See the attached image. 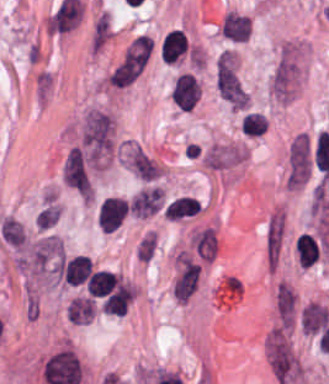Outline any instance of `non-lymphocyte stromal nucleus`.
<instances>
[{"label":"non-lymphocyte stromal nucleus","instance_id":"obj_1","mask_svg":"<svg viewBox=\"0 0 329 384\" xmlns=\"http://www.w3.org/2000/svg\"><path fill=\"white\" fill-rule=\"evenodd\" d=\"M78 146L91 169L108 159L112 147L108 113L89 108L81 119Z\"/></svg>","mask_w":329,"mask_h":384},{"label":"non-lymphocyte stromal nucleus","instance_id":"obj_2","mask_svg":"<svg viewBox=\"0 0 329 384\" xmlns=\"http://www.w3.org/2000/svg\"><path fill=\"white\" fill-rule=\"evenodd\" d=\"M64 249L57 235H43L28 243L20 265L35 274L52 273L61 264Z\"/></svg>","mask_w":329,"mask_h":384},{"label":"non-lymphocyte stromal nucleus","instance_id":"obj_3","mask_svg":"<svg viewBox=\"0 0 329 384\" xmlns=\"http://www.w3.org/2000/svg\"><path fill=\"white\" fill-rule=\"evenodd\" d=\"M150 39L132 38L109 73L110 85L129 86L149 61Z\"/></svg>","mask_w":329,"mask_h":384},{"label":"non-lymphocyte stromal nucleus","instance_id":"obj_4","mask_svg":"<svg viewBox=\"0 0 329 384\" xmlns=\"http://www.w3.org/2000/svg\"><path fill=\"white\" fill-rule=\"evenodd\" d=\"M268 363L281 384L293 382L301 373L299 360L282 335H269Z\"/></svg>","mask_w":329,"mask_h":384},{"label":"non-lymphocyte stromal nucleus","instance_id":"obj_5","mask_svg":"<svg viewBox=\"0 0 329 384\" xmlns=\"http://www.w3.org/2000/svg\"><path fill=\"white\" fill-rule=\"evenodd\" d=\"M286 236V217L278 204L268 214L263 227V260L266 271H274Z\"/></svg>","mask_w":329,"mask_h":384},{"label":"non-lymphocyte stromal nucleus","instance_id":"obj_6","mask_svg":"<svg viewBox=\"0 0 329 384\" xmlns=\"http://www.w3.org/2000/svg\"><path fill=\"white\" fill-rule=\"evenodd\" d=\"M63 181L84 197H92L90 162L84 149L73 147L64 158Z\"/></svg>","mask_w":329,"mask_h":384},{"label":"non-lymphocyte stromal nucleus","instance_id":"obj_7","mask_svg":"<svg viewBox=\"0 0 329 384\" xmlns=\"http://www.w3.org/2000/svg\"><path fill=\"white\" fill-rule=\"evenodd\" d=\"M215 83L219 97H240V79L229 50H222L216 59Z\"/></svg>","mask_w":329,"mask_h":384},{"label":"non-lymphocyte stromal nucleus","instance_id":"obj_8","mask_svg":"<svg viewBox=\"0 0 329 384\" xmlns=\"http://www.w3.org/2000/svg\"><path fill=\"white\" fill-rule=\"evenodd\" d=\"M199 269L195 261L185 252L178 251L175 254L173 292L175 298L187 301L192 294Z\"/></svg>","mask_w":329,"mask_h":384},{"label":"non-lymphocyte stromal nucleus","instance_id":"obj_9","mask_svg":"<svg viewBox=\"0 0 329 384\" xmlns=\"http://www.w3.org/2000/svg\"><path fill=\"white\" fill-rule=\"evenodd\" d=\"M163 208V194L160 186L146 183L128 197V214L145 218Z\"/></svg>","mask_w":329,"mask_h":384},{"label":"non-lymphocyte stromal nucleus","instance_id":"obj_10","mask_svg":"<svg viewBox=\"0 0 329 384\" xmlns=\"http://www.w3.org/2000/svg\"><path fill=\"white\" fill-rule=\"evenodd\" d=\"M96 217L101 229L112 233L126 219V198L107 196L97 206Z\"/></svg>","mask_w":329,"mask_h":384},{"label":"non-lymphocyte stromal nucleus","instance_id":"obj_11","mask_svg":"<svg viewBox=\"0 0 329 384\" xmlns=\"http://www.w3.org/2000/svg\"><path fill=\"white\" fill-rule=\"evenodd\" d=\"M219 30L223 38L232 42L243 43L248 40L250 36V18L235 12H228Z\"/></svg>","mask_w":329,"mask_h":384},{"label":"non-lymphocyte stromal nucleus","instance_id":"obj_12","mask_svg":"<svg viewBox=\"0 0 329 384\" xmlns=\"http://www.w3.org/2000/svg\"><path fill=\"white\" fill-rule=\"evenodd\" d=\"M328 319L326 307L317 301H309L300 310V323L306 334H314L322 329Z\"/></svg>","mask_w":329,"mask_h":384},{"label":"non-lymphocyte stromal nucleus","instance_id":"obj_13","mask_svg":"<svg viewBox=\"0 0 329 384\" xmlns=\"http://www.w3.org/2000/svg\"><path fill=\"white\" fill-rule=\"evenodd\" d=\"M296 297L287 282L280 281L276 285L275 304L277 314L285 325H292Z\"/></svg>","mask_w":329,"mask_h":384},{"label":"non-lymphocyte stromal nucleus","instance_id":"obj_14","mask_svg":"<svg viewBox=\"0 0 329 384\" xmlns=\"http://www.w3.org/2000/svg\"><path fill=\"white\" fill-rule=\"evenodd\" d=\"M129 161L131 169L136 176L148 181L158 177L159 169L140 147L134 145Z\"/></svg>","mask_w":329,"mask_h":384},{"label":"non-lymphocyte stromal nucleus","instance_id":"obj_15","mask_svg":"<svg viewBox=\"0 0 329 384\" xmlns=\"http://www.w3.org/2000/svg\"><path fill=\"white\" fill-rule=\"evenodd\" d=\"M60 217V207L54 197H47L35 215V226L48 230Z\"/></svg>","mask_w":329,"mask_h":384},{"label":"non-lymphocyte stromal nucleus","instance_id":"obj_16","mask_svg":"<svg viewBox=\"0 0 329 384\" xmlns=\"http://www.w3.org/2000/svg\"><path fill=\"white\" fill-rule=\"evenodd\" d=\"M1 238L9 244L19 246L22 244L24 231L22 225L12 217H8L0 224Z\"/></svg>","mask_w":329,"mask_h":384},{"label":"non-lymphocyte stromal nucleus","instance_id":"obj_17","mask_svg":"<svg viewBox=\"0 0 329 384\" xmlns=\"http://www.w3.org/2000/svg\"><path fill=\"white\" fill-rule=\"evenodd\" d=\"M156 249V237L154 234L145 233L136 244L137 256L141 261H149Z\"/></svg>","mask_w":329,"mask_h":384}]
</instances>
